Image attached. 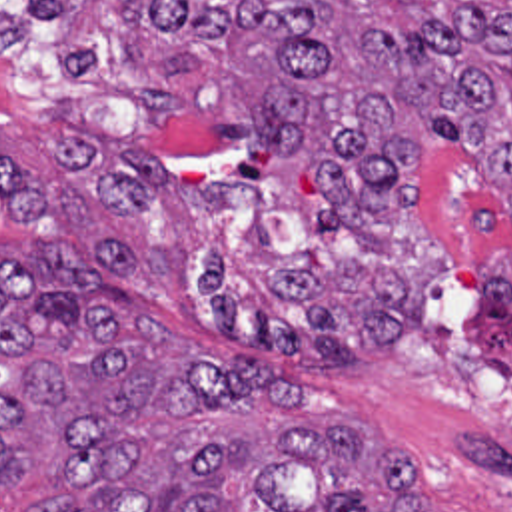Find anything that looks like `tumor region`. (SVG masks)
<instances>
[{
	"label": "tumor region",
	"instance_id": "tumor-region-1",
	"mask_svg": "<svg viewBox=\"0 0 512 512\" xmlns=\"http://www.w3.org/2000/svg\"><path fill=\"white\" fill-rule=\"evenodd\" d=\"M58 20L64 74L178 104L218 134L320 174L318 220L346 228L326 272L248 292L212 248L200 264L220 328L274 358L352 362L398 350L455 264L512 358V0H30ZM28 20L0 6V54ZM463 156L497 212V254L467 266L414 172ZM10 218L50 200L0 154ZM441 250H439V248ZM144 266L96 232L0 256V485L38 469L68 493L24 512H426L410 455L318 426L282 370L166 340L138 308Z\"/></svg>",
	"mask_w": 512,
	"mask_h": 512
}]
</instances>
